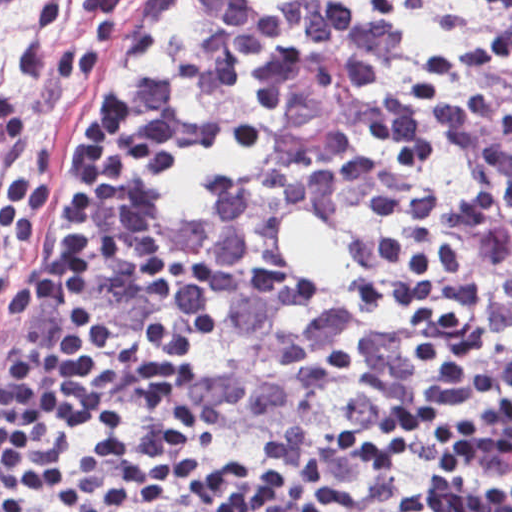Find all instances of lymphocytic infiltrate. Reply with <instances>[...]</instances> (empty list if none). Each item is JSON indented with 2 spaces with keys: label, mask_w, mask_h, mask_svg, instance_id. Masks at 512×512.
I'll use <instances>...</instances> for the list:
<instances>
[{
  "label": "lymphocytic infiltrate",
  "mask_w": 512,
  "mask_h": 512,
  "mask_svg": "<svg viewBox=\"0 0 512 512\" xmlns=\"http://www.w3.org/2000/svg\"><path fill=\"white\" fill-rule=\"evenodd\" d=\"M47 295L87 338L98 191L129 148L104 361L15 352L21 512H512V1H111ZM40 170L0 174L31 251Z\"/></svg>",
  "instance_id": "1"
}]
</instances>
